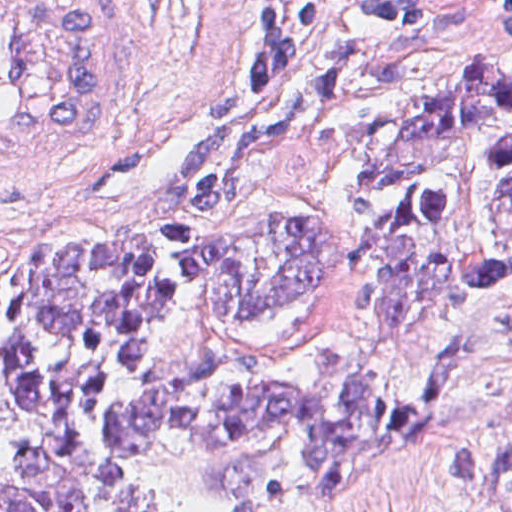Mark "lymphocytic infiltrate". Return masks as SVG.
Segmentation results:
<instances>
[{
  "instance_id": "f902f5d3",
  "label": "lymphocytic infiltrate",
  "mask_w": 512,
  "mask_h": 512,
  "mask_svg": "<svg viewBox=\"0 0 512 512\" xmlns=\"http://www.w3.org/2000/svg\"><path fill=\"white\" fill-rule=\"evenodd\" d=\"M430 6L431 1H267V10L236 49V67L251 90H268L315 52L324 36L415 23L406 34Z\"/></svg>"
}]
</instances>
